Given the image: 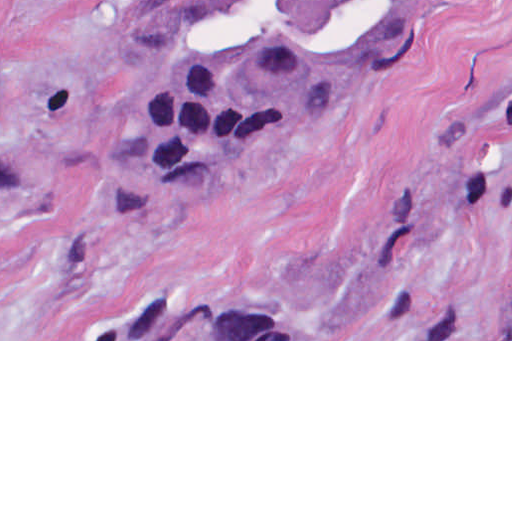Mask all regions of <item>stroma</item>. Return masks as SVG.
<instances>
[{"mask_svg":"<svg viewBox=\"0 0 512 512\" xmlns=\"http://www.w3.org/2000/svg\"><path fill=\"white\" fill-rule=\"evenodd\" d=\"M129 3L0 0V128L55 159L0 162V341H512V0H441L382 79L208 178H167ZM200 299H290L298 339H113Z\"/></svg>","mask_w":512,"mask_h":512,"instance_id":"obj_1","label":"stroma"}]
</instances>
